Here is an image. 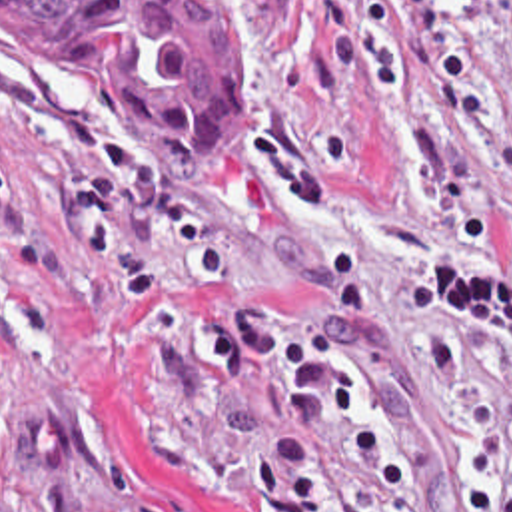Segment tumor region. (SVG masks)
I'll return each instance as SVG.
<instances>
[{
    "instance_id": "1",
    "label": "tumor region",
    "mask_w": 512,
    "mask_h": 512,
    "mask_svg": "<svg viewBox=\"0 0 512 512\" xmlns=\"http://www.w3.org/2000/svg\"><path fill=\"white\" fill-rule=\"evenodd\" d=\"M146 133L166 193L212 199L243 167V58L202 0H0Z\"/></svg>"
}]
</instances>
